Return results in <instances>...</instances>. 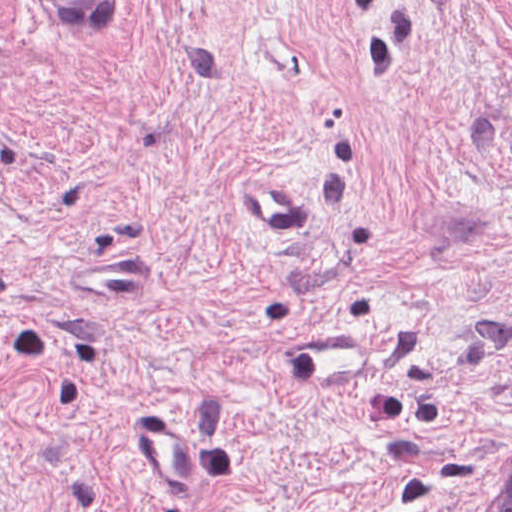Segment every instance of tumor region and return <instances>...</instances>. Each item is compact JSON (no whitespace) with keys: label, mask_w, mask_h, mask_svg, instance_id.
<instances>
[{"label":"tumor region","mask_w":512,"mask_h":512,"mask_svg":"<svg viewBox=\"0 0 512 512\" xmlns=\"http://www.w3.org/2000/svg\"><path fill=\"white\" fill-rule=\"evenodd\" d=\"M80 25H102L123 12V0H48ZM490 512H512V471L490 506Z\"/></svg>","instance_id":"tumor-region-1"}]
</instances>
